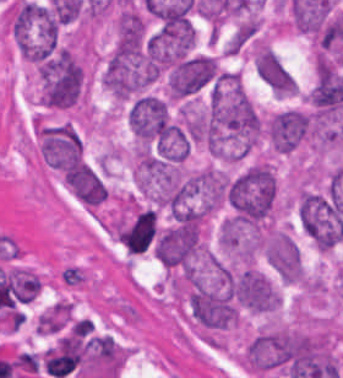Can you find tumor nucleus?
<instances>
[{
    "label": "tumor nucleus",
    "instance_id": "tumor-nucleus-3",
    "mask_svg": "<svg viewBox=\"0 0 343 378\" xmlns=\"http://www.w3.org/2000/svg\"><path fill=\"white\" fill-rule=\"evenodd\" d=\"M40 102L47 107H70L78 98L82 69L68 47L55 51L38 69Z\"/></svg>",
    "mask_w": 343,
    "mask_h": 378
},
{
    "label": "tumor nucleus",
    "instance_id": "tumor-nucleus-5",
    "mask_svg": "<svg viewBox=\"0 0 343 378\" xmlns=\"http://www.w3.org/2000/svg\"><path fill=\"white\" fill-rule=\"evenodd\" d=\"M128 125L139 144L159 143L170 129L163 101L139 96L129 108Z\"/></svg>",
    "mask_w": 343,
    "mask_h": 378
},
{
    "label": "tumor nucleus",
    "instance_id": "tumor-nucleus-1",
    "mask_svg": "<svg viewBox=\"0 0 343 378\" xmlns=\"http://www.w3.org/2000/svg\"><path fill=\"white\" fill-rule=\"evenodd\" d=\"M276 180L267 163H253L228 180L224 199L228 224L259 226L274 208Z\"/></svg>",
    "mask_w": 343,
    "mask_h": 378
},
{
    "label": "tumor nucleus",
    "instance_id": "tumor-nucleus-9",
    "mask_svg": "<svg viewBox=\"0 0 343 378\" xmlns=\"http://www.w3.org/2000/svg\"><path fill=\"white\" fill-rule=\"evenodd\" d=\"M253 66L259 79L278 96H292L296 81L279 56L265 45L255 50Z\"/></svg>",
    "mask_w": 343,
    "mask_h": 378
},
{
    "label": "tumor nucleus",
    "instance_id": "tumor-nucleus-2",
    "mask_svg": "<svg viewBox=\"0 0 343 378\" xmlns=\"http://www.w3.org/2000/svg\"><path fill=\"white\" fill-rule=\"evenodd\" d=\"M8 31L18 54L31 64L59 42L58 18L44 4L14 2Z\"/></svg>",
    "mask_w": 343,
    "mask_h": 378
},
{
    "label": "tumor nucleus",
    "instance_id": "tumor-nucleus-7",
    "mask_svg": "<svg viewBox=\"0 0 343 378\" xmlns=\"http://www.w3.org/2000/svg\"><path fill=\"white\" fill-rule=\"evenodd\" d=\"M216 62L208 56H194L181 60L169 76L172 99L198 91L215 76Z\"/></svg>",
    "mask_w": 343,
    "mask_h": 378
},
{
    "label": "tumor nucleus",
    "instance_id": "tumor-nucleus-8",
    "mask_svg": "<svg viewBox=\"0 0 343 378\" xmlns=\"http://www.w3.org/2000/svg\"><path fill=\"white\" fill-rule=\"evenodd\" d=\"M234 294L241 305L264 311L279 306L280 294L266 277L256 268H247L234 282Z\"/></svg>",
    "mask_w": 343,
    "mask_h": 378
},
{
    "label": "tumor nucleus",
    "instance_id": "tumor-nucleus-4",
    "mask_svg": "<svg viewBox=\"0 0 343 378\" xmlns=\"http://www.w3.org/2000/svg\"><path fill=\"white\" fill-rule=\"evenodd\" d=\"M264 126L268 143L289 153L310 136L314 121L310 111L289 107L268 116Z\"/></svg>",
    "mask_w": 343,
    "mask_h": 378
},
{
    "label": "tumor nucleus",
    "instance_id": "tumor-nucleus-6",
    "mask_svg": "<svg viewBox=\"0 0 343 378\" xmlns=\"http://www.w3.org/2000/svg\"><path fill=\"white\" fill-rule=\"evenodd\" d=\"M267 263L286 284L302 280L298 248L285 231L273 230L263 238Z\"/></svg>",
    "mask_w": 343,
    "mask_h": 378
}]
</instances>
